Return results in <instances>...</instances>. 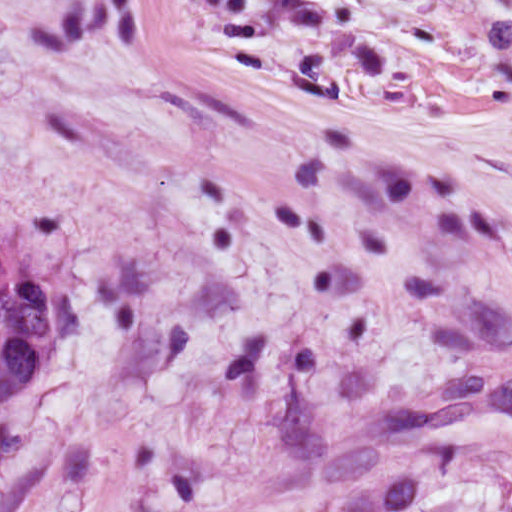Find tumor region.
Masks as SVG:
<instances>
[{
  "mask_svg": "<svg viewBox=\"0 0 512 512\" xmlns=\"http://www.w3.org/2000/svg\"><path fill=\"white\" fill-rule=\"evenodd\" d=\"M84 336V307L58 255L0 220V419L40 394ZM321 512H424V474L392 471Z\"/></svg>",
  "mask_w": 512,
  "mask_h": 512,
  "instance_id": "tumor-region-1",
  "label": "tumor region"
}]
</instances>
